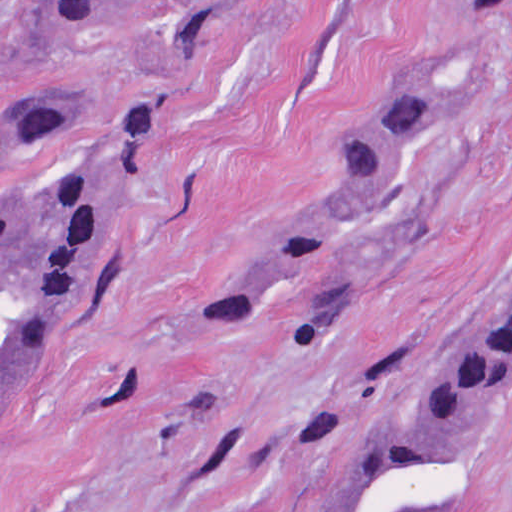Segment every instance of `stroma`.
<instances>
[{
  "mask_svg": "<svg viewBox=\"0 0 512 512\" xmlns=\"http://www.w3.org/2000/svg\"><path fill=\"white\" fill-rule=\"evenodd\" d=\"M388 87L428 105L337 233L326 309L298 330L287 272L237 331L192 328L325 214ZM31 101L72 118V149L141 166V195L0 433V512H318L512 287V8L0 0V147ZM432 512H512V363Z\"/></svg>",
  "mask_w": 512,
  "mask_h": 512,
  "instance_id": "35a3bbf8",
  "label": "stroma"
}]
</instances>
